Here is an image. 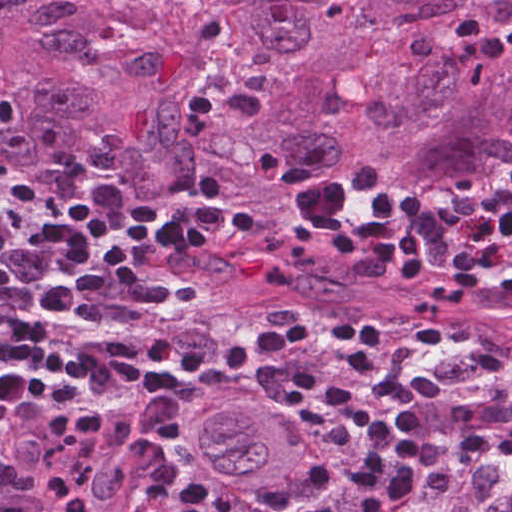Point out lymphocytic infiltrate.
<instances>
[{
	"label": "lymphocytic infiltrate",
	"mask_w": 512,
	"mask_h": 512,
	"mask_svg": "<svg viewBox=\"0 0 512 512\" xmlns=\"http://www.w3.org/2000/svg\"><path fill=\"white\" fill-rule=\"evenodd\" d=\"M423 198L424 192L384 189L369 203L360 222L342 227L336 234L335 255L390 266L409 283L422 281L432 269L436 234V228L423 216ZM226 205L224 187L218 178L209 176L202 182L192 220L163 224L199 256L219 238L249 242L256 233L255 219L241 212H228ZM437 209L443 220L457 225L472 247L458 251L456 273L438 285L437 299L457 305L475 285L497 298L512 299V280L497 285L491 277L506 259L498 248L512 240V167L477 195L450 199ZM382 330L378 321L365 317L339 326L292 317L285 334L300 347L316 340L352 343L346 353L349 367L368 374L371 395L386 404L398 432L419 425L422 410L431 405L474 397L502 370V356L489 350L469 368L466 380L440 383L434 377L432 360L443 343L444 329L434 323L409 341L407 347L417 367L413 375L401 377L379 353ZM459 448L473 457H512V411L486 429L466 433ZM510 507L512 512V498Z\"/></svg>",
	"instance_id": "f902f5d3"
}]
</instances>
